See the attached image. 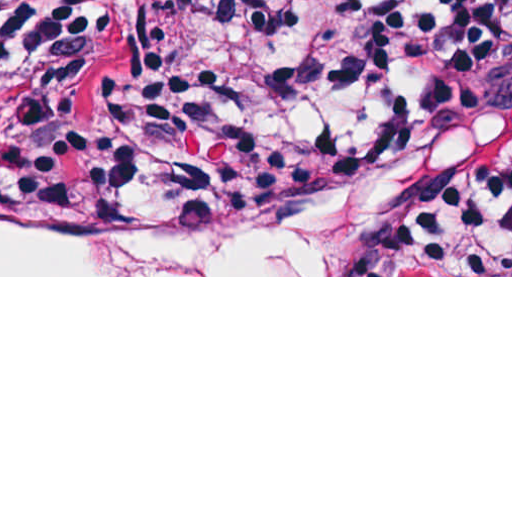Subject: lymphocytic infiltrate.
Wrapping results in <instances>:
<instances>
[{"mask_svg":"<svg viewBox=\"0 0 512 512\" xmlns=\"http://www.w3.org/2000/svg\"><path fill=\"white\" fill-rule=\"evenodd\" d=\"M510 0H0L36 88L4 159L54 191L227 225L264 222L406 136L425 27ZM433 127L512 120V28L433 71ZM459 275H512V174L450 228Z\"/></svg>","mask_w":512,"mask_h":512,"instance_id":"lymphocytic-infiltrate-1","label":"lymphocytic infiltrate"}]
</instances>
